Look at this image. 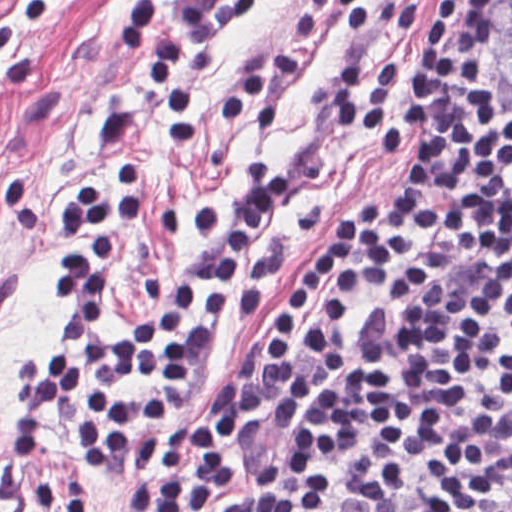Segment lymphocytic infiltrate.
Returning <instances> with one entry per match:
<instances>
[{"label": "lymphocytic infiltrate", "mask_w": 512, "mask_h": 512, "mask_svg": "<svg viewBox=\"0 0 512 512\" xmlns=\"http://www.w3.org/2000/svg\"><path fill=\"white\" fill-rule=\"evenodd\" d=\"M56 1L11 0L0 85L29 83L16 26L40 24ZM261 1L179 0L175 18L212 43ZM496 1L443 0L412 55L414 95L389 55L356 58L335 79L332 117L399 167L343 212L301 279L257 256L234 315L255 321L275 300L205 422L189 401L209 377V340L231 314L250 238L295 186L279 162H246L237 201L195 228L203 253L116 340L115 266L146 216L148 136L140 111L102 115L104 174L48 218L62 248L52 343L25 367L8 443L38 461L57 414L101 471L130 478L120 512H217L247 483L261 433L302 424L240 512H512V108L493 115L485 87ZM166 2L134 0L121 44L159 79L162 131L192 143L194 94L161 33ZM367 307L385 312L353 350ZM32 496L41 512H102L76 482Z\"/></svg>", "instance_id": "1"}]
</instances>
